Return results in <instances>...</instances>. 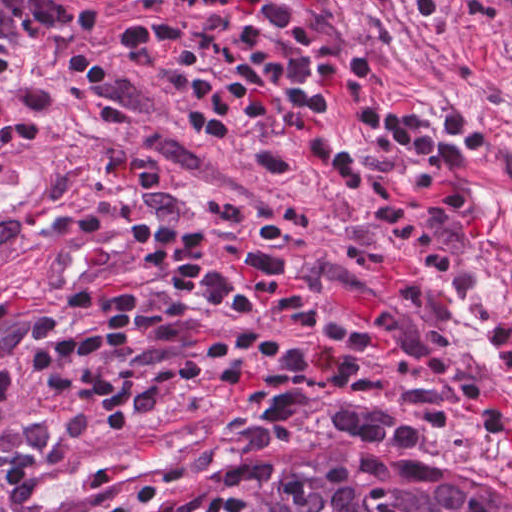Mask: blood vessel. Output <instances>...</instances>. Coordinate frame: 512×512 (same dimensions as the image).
<instances>
[{
  "mask_svg": "<svg viewBox=\"0 0 512 512\" xmlns=\"http://www.w3.org/2000/svg\"><path fill=\"white\" fill-rule=\"evenodd\" d=\"M241 411L223 396L192 400L81 445L49 462L7 512H94L152 478L174 471L237 428Z\"/></svg>",
  "mask_w": 512,
  "mask_h": 512,
  "instance_id": "1",
  "label": "blood vessel"
}]
</instances>
